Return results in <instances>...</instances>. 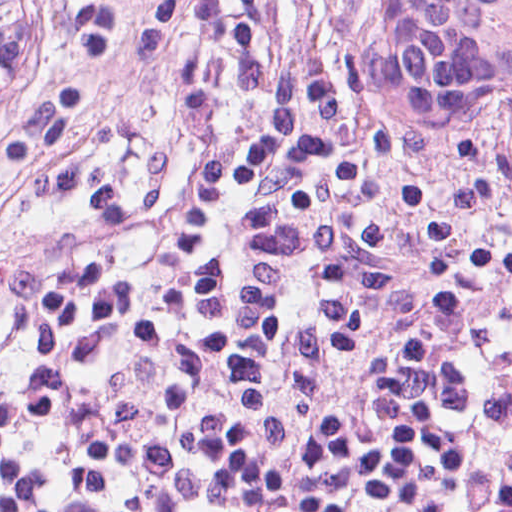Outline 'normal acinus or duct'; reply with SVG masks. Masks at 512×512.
Returning a JSON list of instances; mask_svg holds the SVG:
<instances>
[{"mask_svg": "<svg viewBox=\"0 0 512 512\" xmlns=\"http://www.w3.org/2000/svg\"><path fill=\"white\" fill-rule=\"evenodd\" d=\"M42 0H0V89Z\"/></svg>", "mask_w": 512, "mask_h": 512, "instance_id": "1", "label": "normal acinus or duct"}]
</instances>
